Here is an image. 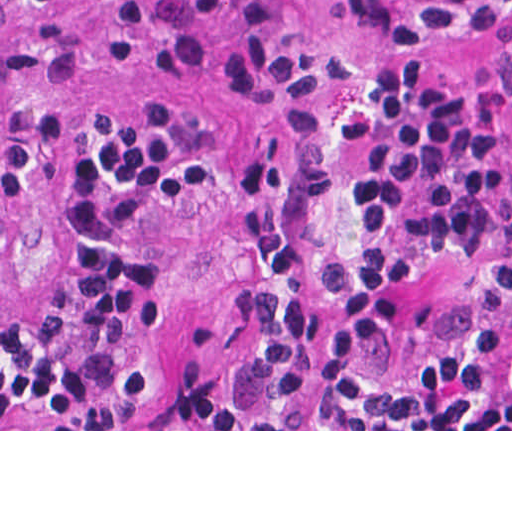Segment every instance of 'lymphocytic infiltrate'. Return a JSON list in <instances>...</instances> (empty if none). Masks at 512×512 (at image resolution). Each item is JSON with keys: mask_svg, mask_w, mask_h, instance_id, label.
<instances>
[{"mask_svg": "<svg viewBox=\"0 0 512 512\" xmlns=\"http://www.w3.org/2000/svg\"><path fill=\"white\" fill-rule=\"evenodd\" d=\"M103 1L135 18L147 2ZM477 2L489 24H512V0ZM418 3L333 0L310 20L282 0H190L167 35L171 68L192 75L219 52L256 123L230 223L237 298L196 346L162 351L161 242L203 181L188 177L166 109L118 110L75 146L58 301L36 313L0 302V429H398L512 403V269L440 356L383 363L405 272L338 242L345 144L358 140L366 213L408 246L459 248L483 218L474 138L446 87L370 83L364 69L360 52H437ZM23 156L0 90V243Z\"/></svg>", "mask_w": 512, "mask_h": 512, "instance_id": "obj_1", "label": "lymphocytic infiltrate"}]
</instances>
